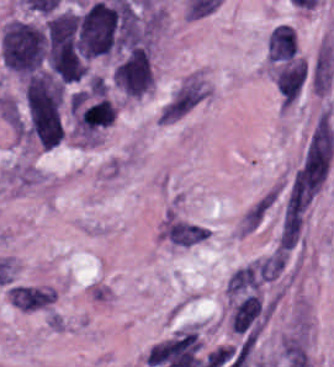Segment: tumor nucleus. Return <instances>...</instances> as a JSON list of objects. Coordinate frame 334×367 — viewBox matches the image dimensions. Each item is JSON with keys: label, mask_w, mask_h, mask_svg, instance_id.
<instances>
[{"label": "tumor nucleus", "mask_w": 334, "mask_h": 367, "mask_svg": "<svg viewBox=\"0 0 334 367\" xmlns=\"http://www.w3.org/2000/svg\"><path fill=\"white\" fill-rule=\"evenodd\" d=\"M114 85L127 97L138 98L153 87L147 48L135 47L114 68Z\"/></svg>", "instance_id": "3"}, {"label": "tumor nucleus", "mask_w": 334, "mask_h": 367, "mask_svg": "<svg viewBox=\"0 0 334 367\" xmlns=\"http://www.w3.org/2000/svg\"><path fill=\"white\" fill-rule=\"evenodd\" d=\"M23 134L42 149L63 136V88L54 78L36 75L25 84Z\"/></svg>", "instance_id": "1"}, {"label": "tumor nucleus", "mask_w": 334, "mask_h": 367, "mask_svg": "<svg viewBox=\"0 0 334 367\" xmlns=\"http://www.w3.org/2000/svg\"><path fill=\"white\" fill-rule=\"evenodd\" d=\"M44 36L41 28L18 19H11L0 36L1 61L5 67L29 72L42 59Z\"/></svg>", "instance_id": "2"}]
</instances>
